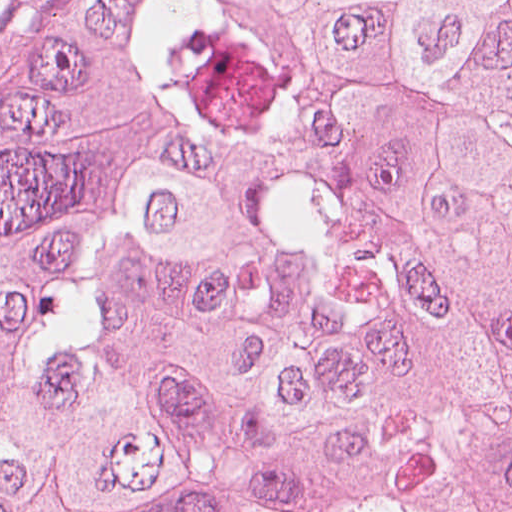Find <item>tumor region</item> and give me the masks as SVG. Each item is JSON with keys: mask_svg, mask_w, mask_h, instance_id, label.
I'll return each mask as SVG.
<instances>
[{"mask_svg": "<svg viewBox=\"0 0 512 512\" xmlns=\"http://www.w3.org/2000/svg\"><path fill=\"white\" fill-rule=\"evenodd\" d=\"M0 512H512V0H77L0 122Z\"/></svg>", "mask_w": 512, "mask_h": 512, "instance_id": "1", "label": "tumor region"}]
</instances>
